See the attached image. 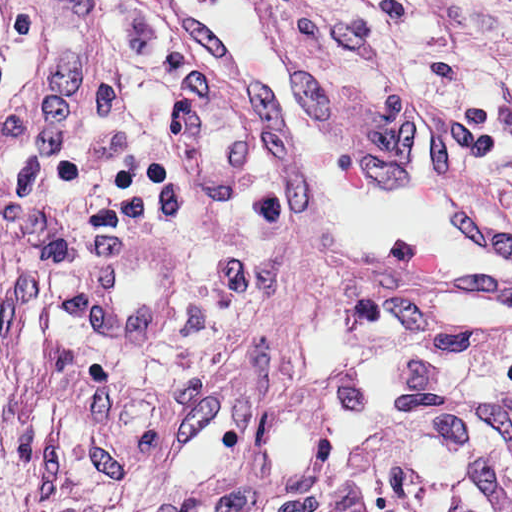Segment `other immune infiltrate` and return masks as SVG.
<instances>
[{"instance_id": "bc1004c8", "label": "other immune infiltrate", "mask_w": 512, "mask_h": 512, "mask_svg": "<svg viewBox=\"0 0 512 512\" xmlns=\"http://www.w3.org/2000/svg\"><path fill=\"white\" fill-rule=\"evenodd\" d=\"M245 512H512V388L389 390L341 425L293 488Z\"/></svg>"}]
</instances>
